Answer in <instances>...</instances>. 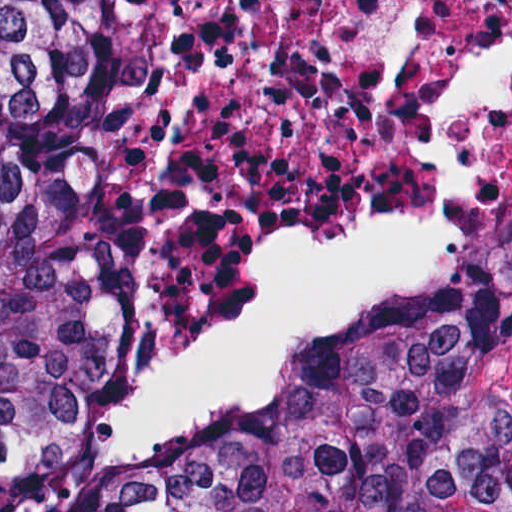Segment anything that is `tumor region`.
Instances as JSON below:
<instances>
[{
  "instance_id": "e687c5a6",
  "label": "tumor region",
  "mask_w": 512,
  "mask_h": 512,
  "mask_svg": "<svg viewBox=\"0 0 512 512\" xmlns=\"http://www.w3.org/2000/svg\"><path fill=\"white\" fill-rule=\"evenodd\" d=\"M96 120L67 0H0V512H512L509 263L475 265L161 476L94 463L73 291Z\"/></svg>"
}]
</instances>
